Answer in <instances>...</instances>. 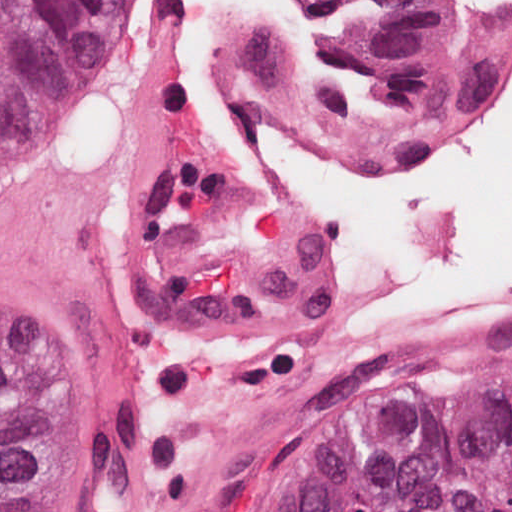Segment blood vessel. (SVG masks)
I'll use <instances>...</instances> for the list:
<instances>
[{"label":"blood vessel","instance_id":"1","mask_svg":"<svg viewBox=\"0 0 512 512\" xmlns=\"http://www.w3.org/2000/svg\"><path fill=\"white\" fill-rule=\"evenodd\" d=\"M481 1L512 28V5ZM338 289L262 155L188 91L178 0H149L106 131L34 222H0V331L108 428L113 512H253L299 397L401 347L325 349ZM507 323L512 310L434 338Z\"/></svg>","mask_w":512,"mask_h":512}]
</instances>
